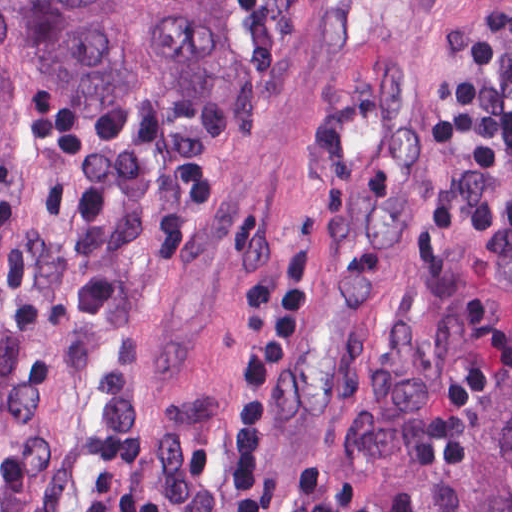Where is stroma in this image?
Masks as SVG:
<instances>
[{
    "mask_svg": "<svg viewBox=\"0 0 512 512\" xmlns=\"http://www.w3.org/2000/svg\"><path fill=\"white\" fill-rule=\"evenodd\" d=\"M512 0H237L178 131L136 304V424L67 437L50 512L110 471L160 512H231L237 362L311 208L306 308L270 382L265 474L316 463L373 512H437L512 382V189L448 125Z\"/></svg>",
    "mask_w": 512,
    "mask_h": 512,
    "instance_id": "1",
    "label": "stroma"
}]
</instances>
